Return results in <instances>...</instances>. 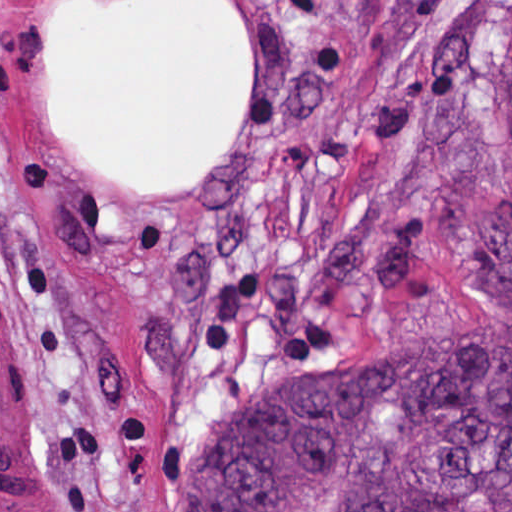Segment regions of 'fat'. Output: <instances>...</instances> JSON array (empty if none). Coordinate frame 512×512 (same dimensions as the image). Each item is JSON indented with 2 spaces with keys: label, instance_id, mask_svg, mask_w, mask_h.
Segmentation results:
<instances>
[{
  "label": "fat",
  "instance_id": "obj_1",
  "mask_svg": "<svg viewBox=\"0 0 512 512\" xmlns=\"http://www.w3.org/2000/svg\"><path fill=\"white\" fill-rule=\"evenodd\" d=\"M49 93L87 158L126 181H186L235 143L249 94V30L228 0L64 10Z\"/></svg>",
  "mask_w": 512,
  "mask_h": 512
}]
</instances>
